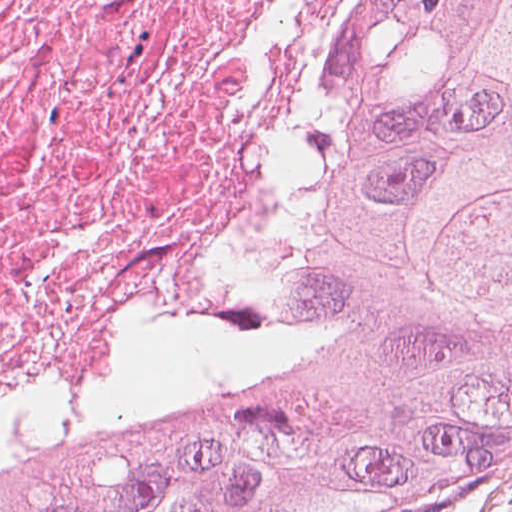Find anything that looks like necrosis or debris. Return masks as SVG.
I'll use <instances>...</instances> for the list:
<instances>
[{
    "mask_svg": "<svg viewBox=\"0 0 512 512\" xmlns=\"http://www.w3.org/2000/svg\"><path fill=\"white\" fill-rule=\"evenodd\" d=\"M395 0H0V488L277 294Z\"/></svg>",
    "mask_w": 512,
    "mask_h": 512,
    "instance_id": "obj_1",
    "label": "necrosis or debris"
}]
</instances>
